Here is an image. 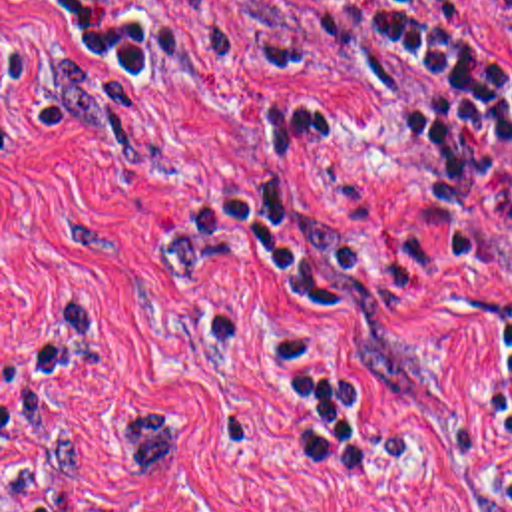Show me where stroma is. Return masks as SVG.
<instances>
[{
  "mask_svg": "<svg viewBox=\"0 0 512 512\" xmlns=\"http://www.w3.org/2000/svg\"><path fill=\"white\" fill-rule=\"evenodd\" d=\"M512 59L504 0H470ZM84 51L114 153L74 135L54 59ZM301 101L323 139L265 151L243 107ZM430 121L354 79L285 67L271 0H0V512H512L486 416L482 320L512 304V153L480 244L406 202ZM259 181L356 236L337 314L199 252L203 192ZM181 429L143 483L114 420Z\"/></svg>",
  "mask_w": 512,
  "mask_h": 512,
  "instance_id": "stroma-1",
  "label": "stroma"
}]
</instances>
